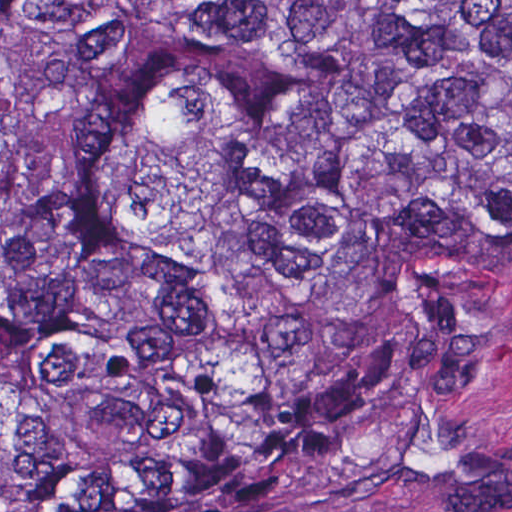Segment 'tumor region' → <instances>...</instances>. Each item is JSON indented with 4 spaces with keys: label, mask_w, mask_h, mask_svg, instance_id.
<instances>
[{
    "label": "tumor region",
    "mask_w": 512,
    "mask_h": 512,
    "mask_svg": "<svg viewBox=\"0 0 512 512\" xmlns=\"http://www.w3.org/2000/svg\"><path fill=\"white\" fill-rule=\"evenodd\" d=\"M512 308V0H0V512H319Z\"/></svg>",
    "instance_id": "1"
}]
</instances>
